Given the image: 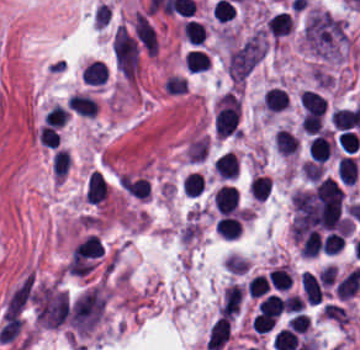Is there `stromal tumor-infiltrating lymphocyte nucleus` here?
<instances>
[{
  "label": "stromal tumor-infiltrating lymphocyte nucleus",
  "mask_w": 360,
  "mask_h": 350,
  "mask_svg": "<svg viewBox=\"0 0 360 350\" xmlns=\"http://www.w3.org/2000/svg\"><path fill=\"white\" fill-rule=\"evenodd\" d=\"M216 208L223 214L237 209L238 193L234 185L221 184L212 194Z\"/></svg>",
  "instance_id": "3"
},
{
  "label": "stromal tumor-infiltrating lymphocyte nucleus",
  "mask_w": 360,
  "mask_h": 350,
  "mask_svg": "<svg viewBox=\"0 0 360 350\" xmlns=\"http://www.w3.org/2000/svg\"><path fill=\"white\" fill-rule=\"evenodd\" d=\"M286 106V91L279 85H271L265 89L264 108L279 111Z\"/></svg>",
  "instance_id": "12"
},
{
  "label": "stromal tumor-infiltrating lymphocyte nucleus",
  "mask_w": 360,
  "mask_h": 350,
  "mask_svg": "<svg viewBox=\"0 0 360 350\" xmlns=\"http://www.w3.org/2000/svg\"><path fill=\"white\" fill-rule=\"evenodd\" d=\"M70 161L69 150L65 148H58L55 150L52 172L55 179L64 178Z\"/></svg>",
  "instance_id": "18"
},
{
  "label": "stromal tumor-infiltrating lymphocyte nucleus",
  "mask_w": 360,
  "mask_h": 350,
  "mask_svg": "<svg viewBox=\"0 0 360 350\" xmlns=\"http://www.w3.org/2000/svg\"><path fill=\"white\" fill-rule=\"evenodd\" d=\"M82 80L85 84L103 85L108 78V69L105 62L92 60L83 70Z\"/></svg>",
  "instance_id": "9"
},
{
  "label": "stromal tumor-infiltrating lymphocyte nucleus",
  "mask_w": 360,
  "mask_h": 350,
  "mask_svg": "<svg viewBox=\"0 0 360 350\" xmlns=\"http://www.w3.org/2000/svg\"><path fill=\"white\" fill-rule=\"evenodd\" d=\"M70 110L85 116H93L97 112V101L86 92H73L68 99Z\"/></svg>",
  "instance_id": "8"
},
{
  "label": "stromal tumor-infiltrating lymphocyte nucleus",
  "mask_w": 360,
  "mask_h": 350,
  "mask_svg": "<svg viewBox=\"0 0 360 350\" xmlns=\"http://www.w3.org/2000/svg\"><path fill=\"white\" fill-rule=\"evenodd\" d=\"M67 115L68 113L63 109V107L54 102L45 112L43 119L48 124L59 128L65 122Z\"/></svg>",
  "instance_id": "21"
},
{
  "label": "stromal tumor-infiltrating lymphocyte nucleus",
  "mask_w": 360,
  "mask_h": 350,
  "mask_svg": "<svg viewBox=\"0 0 360 350\" xmlns=\"http://www.w3.org/2000/svg\"><path fill=\"white\" fill-rule=\"evenodd\" d=\"M333 149V140L329 132L315 134L307 141V151L311 158L322 163L331 155Z\"/></svg>",
  "instance_id": "2"
},
{
  "label": "stromal tumor-infiltrating lymphocyte nucleus",
  "mask_w": 360,
  "mask_h": 350,
  "mask_svg": "<svg viewBox=\"0 0 360 350\" xmlns=\"http://www.w3.org/2000/svg\"><path fill=\"white\" fill-rule=\"evenodd\" d=\"M163 87L170 95H180L186 89V82L181 75L168 74Z\"/></svg>",
  "instance_id": "22"
},
{
  "label": "stromal tumor-infiltrating lymphocyte nucleus",
  "mask_w": 360,
  "mask_h": 350,
  "mask_svg": "<svg viewBox=\"0 0 360 350\" xmlns=\"http://www.w3.org/2000/svg\"><path fill=\"white\" fill-rule=\"evenodd\" d=\"M329 121L334 128L348 129L351 121L346 107H339L329 113Z\"/></svg>",
  "instance_id": "25"
},
{
  "label": "stromal tumor-infiltrating lymphocyte nucleus",
  "mask_w": 360,
  "mask_h": 350,
  "mask_svg": "<svg viewBox=\"0 0 360 350\" xmlns=\"http://www.w3.org/2000/svg\"><path fill=\"white\" fill-rule=\"evenodd\" d=\"M344 244L343 233L329 231L322 239L320 246L326 254H334L342 248Z\"/></svg>",
  "instance_id": "20"
},
{
  "label": "stromal tumor-infiltrating lymphocyte nucleus",
  "mask_w": 360,
  "mask_h": 350,
  "mask_svg": "<svg viewBox=\"0 0 360 350\" xmlns=\"http://www.w3.org/2000/svg\"><path fill=\"white\" fill-rule=\"evenodd\" d=\"M84 200L94 206H101L108 197L107 178L101 170L91 169L85 177Z\"/></svg>",
  "instance_id": "1"
},
{
  "label": "stromal tumor-infiltrating lymphocyte nucleus",
  "mask_w": 360,
  "mask_h": 350,
  "mask_svg": "<svg viewBox=\"0 0 360 350\" xmlns=\"http://www.w3.org/2000/svg\"><path fill=\"white\" fill-rule=\"evenodd\" d=\"M213 166L221 179H233L237 176L238 159L237 154L229 149L216 157Z\"/></svg>",
  "instance_id": "6"
},
{
  "label": "stromal tumor-infiltrating lymphocyte nucleus",
  "mask_w": 360,
  "mask_h": 350,
  "mask_svg": "<svg viewBox=\"0 0 360 350\" xmlns=\"http://www.w3.org/2000/svg\"><path fill=\"white\" fill-rule=\"evenodd\" d=\"M274 145L281 154H289L297 149L291 132L278 128L273 135Z\"/></svg>",
  "instance_id": "15"
},
{
  "label": "stromal tumor-infiltrating lymphocyte nucleus",
  "mask_w": 360,
  "mask_h": 350,
  "mask_svg": "<svg viewBox=\"0 0 360 350\" xmlns=\"http://www.w3.org/2000/svg\"><path fill=\"white\" fill-rule=\"evenodd\" d=\"M184 38L193 44H201L205 36L202 22L186 18L183 22Z\"/></svg>",
  "instance_id": "14"
},
{
  "label": "stromal tumor-infiltrating lymphocyte nucleus",
  "mask_w": 360,
  "mask_h": 350,
  "mask_svg": "<svg viewBox=\"0 0 360 350\" xmlns=\"http://www.w3.org/2000/svg\"><path fill=\"white\" fill-rule=\"evenodd\" d=\"M38 140L48 148H55L59 142V136L56 130L47 123L38 129Z\"/></svg>",
  "instance_id": "23"
},
{
  "label": "stromal tumor-infiltrating lymphocyte nucleus",
  "mask_w": 360,
  "mask_h": 350,
  "mask_svg": "<svg viewBox=\"0 0 360 350\" xmlns=\"http://www.w3.org/2000/svg\"><path fill=\"white\" fill-rule=\"evenodd\" d=\"M359 279L360 268L354 266L337 280L334 293L342 300H349L357 289Z\"/></svg>",
  "instance_id": "5"
},
{
  "label": "stromal tumor-infiltrating lymphocyte nucleus",
  "mask_w": 360,
  "mask_h": 350,
  "mask_svg": "<svg viewBox=\"0 0 360 350\" xmlns=\"http://www.w3.org/2000/svg\"><path fill=\"white\" fill-rule=\"evenodd\" d=\"M242 225L238 212L224 213L218 217L215 232L227 239H237L241 233Z\"/></svg>",
  "instance_id": "4"
},
{
  "label": "stromal tumor-infiltrating lymphocyte nucleus",
  "mask_w": 360,
  "mask_h": 350,
  "mask_svg": "<svg viewBox=\"0 0 360 350\" xmlns=\"http://www.w3.org/2000/svg\"><path fill=\"white\" fill-rule=\"evenodd\" d=\"M181 187L186 195H200L203 189V176L201 173L189 171L181 180Z\"/></svg>",
  "instance_id": "16"
},
{
  "label": "stromal tumor-infiltrating lymphocyte nucleus",
  "mask_w": 360,
  "mask_h": 350,
  "mask_svg": "<svg viewBox=\"0 0 360 350\" xmlns=\"http://www.w3.org/2000/svg\"><path fill=\"white\" fill-rule=\"evenodd\" d=\"M209 64L208 54L198 48H191L185 52L184 65L186 70H206Z\"/></svg>",
  "instance_id": "13"
},
{
  "label": "stromal tumor-infiltrating lymphocyte nucleus",
  "mask_w": 360,
  "mask_h": 350,
  "mask_svg": "<svg viewBox=\"0 0 360 350\" xmlns=\"http://www.w3.org/2000/svg\"><path fill=\"white\" fill-rule=\"evenodd\" d=\"M292 25L288 12L276 11L265 21V28L271 35L282 36L290 32Z\"/></svg>",
  "instance_id": "10"
},
{
  "label": "stromal tumor-infiltrating lymphocyte nucleus",
  "mask_w": 360,
  "mask_h": 350,
  "mask_svg": "<svg viewBox=\"0 0 360 350\" xmlns=\"http://www.w3.org/2000/svg\"><path fill=\"white\" fill-rule=\"evenodd\" d=\"M321 240L322 238L317 231H310L301 240L299 249L302 255L316 256L320 248Z\"/></svg>",
  "instance_id": "19"
},
{
  "label": "stromal tumor-infiltrating lymphocyte nucleus",
  "mask_w": 360,
  "mask_h": 350,
  "mask_svg": "<svg viewBox=\"0 0 360 350\" xmlns=\"http://www.w3.org/2000/svg\"><path fill=\"white\" fill-rule=\"evenodd\" d=\"M212 10L215 18L222 22L230 19L235 12L233 5L223 0H216Z\"/></svg>",
  "instance_id": "26"
},
{
  "label": "stromal tumor-infiltrating lymphocyte nucleus",
  "mask_w": 360,
  "mask_h": 350,
  "mask_svg": "<svg viewBox=\"0 0 360 350\" xmlns=\"http://www.w3.org/2000/svg\"><path fill=\"white\" fill-rule=\"evenodd\" d=\"M359 137L349 129H342L337 136V143L342 150L355 152L358 148Z\"/></svg>",
  "instance_id": "24"
},
{
  "label": "stromal tumor-infiltrating lymphocyte nucleus",
  "mask_w": 360,
  "mask_h": 350,
  "mask_svg": "<svg viewBox=\"0 0 360 350\" xmlns=\"http://www.w3.org/2000/svg\"><path fill=\"white\" fill-rule=\"evenodd\" d=\"M266 279L274 290H287L291 285V271L285 265L271 268L266 274Z\"/></svg>",
  "instance_id": "11"
},
{
  "label": "stromal tumor-infiltrating lymphocyte nucleus",
  "mask_w": 360,
  "mask_h": 350,
  "mask_svg": "<svg viewBox=\"0 0 360 350\" xmlns=\"http://www.w3.org/2000/svg\"><path fill=\"white\" fill-rule=\"evenodd\" d=\"M337 173L340 182L352 184L359 177V163L354 155H340L337 163Z\"/></svg>",
  "instance_id": "7"
},
{
  "label": "stromal tumor-infiltrating lymphocyte nucleus",
  "mask_w": 360,
  "mask_h": 350,
  "mask_svg": "<svg viewBox=\"0 0 360 350\" xmlns=\"http://www.w3.org/2000/svg\"><path fill=\"white\" fill-rule=\"evenodd\" d=\"M271 189V178L261 174H254L249 181L250 195L254 198L264 199Z\"/></svg>",
  "instance_id": "17"
}]
</instances>
